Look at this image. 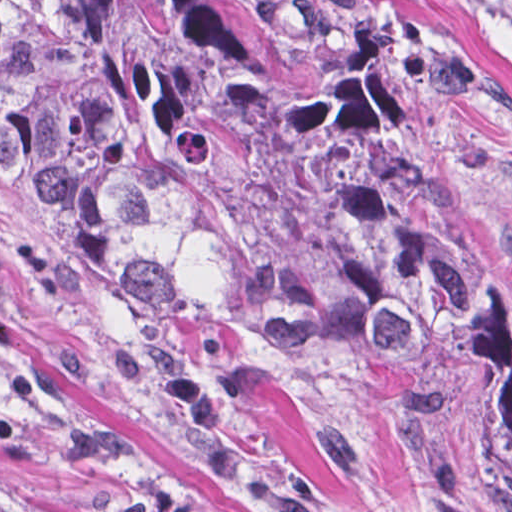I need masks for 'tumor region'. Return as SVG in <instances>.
<instances>
[{"label": "tumor region", "mask_w": 512, "mask_h": 512, "mask_svg": "<svg viewBox=\"0 0 512 512\" xmlns=\"http://www.w3.org/2000/svg\"><path fill=\"white\" fill-rule=\"evenodd\" d=\"M0 174L148 350L432 390L512 488V263L338 42L240 0H0Z\"/></svg>", "instance_id": "tumor-region-1"}]
</instances>
